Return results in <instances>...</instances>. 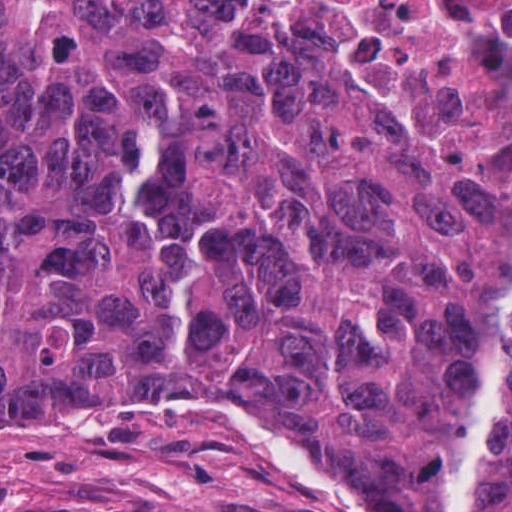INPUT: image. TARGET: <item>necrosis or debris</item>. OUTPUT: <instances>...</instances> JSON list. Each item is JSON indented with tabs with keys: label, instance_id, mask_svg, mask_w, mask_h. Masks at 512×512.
<instances>
[{
	"label": "necrosis or debris",
	"instance_id": "obj_1",
	"mask_svg": "<svg viewBox=\"0 0 512 512\" xmlns=\"http://www.w3.org/2000/svg\"><path fill=\"white\" fill-rule=\"evenodd\" d=\"M322 65L512 203V0H206Z\"/></svg>",
	"mask_w": 512,
	"mask_h": 512
}]
</instances>
